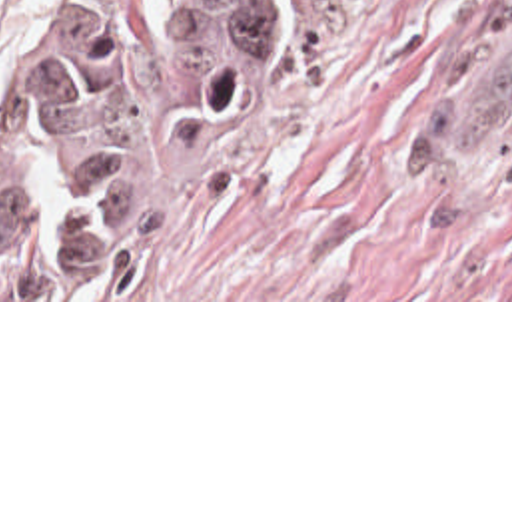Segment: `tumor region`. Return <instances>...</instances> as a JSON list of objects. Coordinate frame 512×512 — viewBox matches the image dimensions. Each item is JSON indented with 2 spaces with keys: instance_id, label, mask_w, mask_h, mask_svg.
Listing matches in <instances>:
<instances>
[{
  "instance_id": "tumor-region-1",
  "label": "tumor region",
  "mask_w": 512,
  "mask_h": 512,
  "mask_svg": "<svg viewBox=\"0 0 512 512\" xmlns=\"http://www.w3.org/2000/svg\"><path fill=\"white\" fill-rule=\"evenodd\" d=\"M169 68L189 96H231L273 66V0H163ZM161 150L139 44L117 0L35 15L5 68L0 284L111 276L153 232Z\"/></svg>"
}]
</instances>
